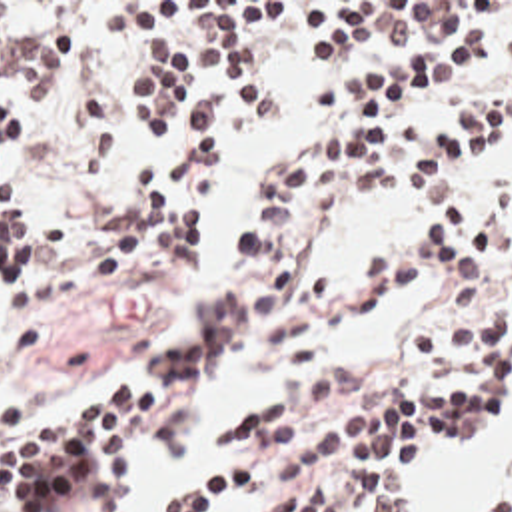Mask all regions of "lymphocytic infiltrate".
Wrapping results in <instances>:
<instances>
[{"label": "lymphocytic infiltrate", "mask_w": 512, "mask_h": 512, "mask_svg": "<svg viewBox=\"0 0 512 512\" xmlns=\"http://www.w3.org/2000/svg\"><path fill=\"white\" fill-rule=\"evenodd\" d=\"M84 2H0V68L54 96L78 58ZM134 58H158L156 76L126 96L144 146L166 132L194 80L210 76L252 122H268L262 86L248 68V30L288 24L304 62L344 64L358 42L414 30L402 56L356 80L310 90V116L342 112L314 148L266 164L264 190L234 224L240 268L216 288L158 365L92 411L28 423L0 397V512H124L116 457L136 445L176 393L250 337L256 353L288 363L324 359L362 308L442 270L456 286L512 278V186L480 196L456 170L510 134V106L474 108L466 130L430 128L400 112L472 78L490 60L488 34L452 36L454 2H178L164 16L124 6ZM512 62V28L500 38ZM34 144L32 104L0 108V335L21 317L70 302L52 264L30 258V218L7 204L13 174ZM478 152V154H466ZM218 160V142H192L144 164L134 218L96 256L102 284L154 260L156 242L198 256L202 218L184 208L188 176ZM426 188L432 226L370 250L342 274L304 264L342 214L402 186ZM420 383H386L358 361L324 381L266 393L226 415L212 445L234 469L176 497L164 512H216L256 477L276 479L272 512H406L412 477L428 451H474L512 433V310L504 290L464 288L416 327ZM484 512H512V491Z\"/></svg>", "instance_id": "1"}]
</instances>
